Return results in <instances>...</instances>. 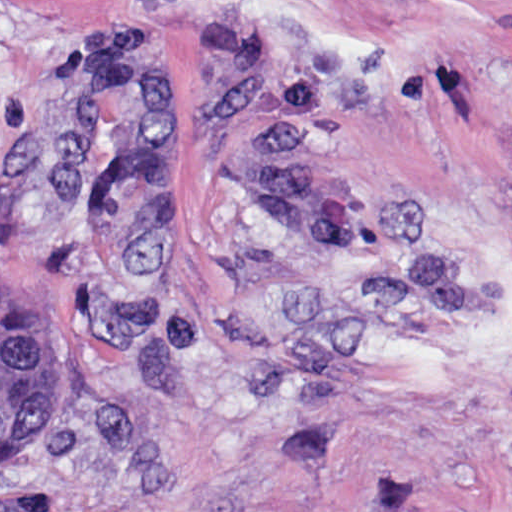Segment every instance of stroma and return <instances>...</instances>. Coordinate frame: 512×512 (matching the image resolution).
I'll return each mask as SVG.
<instances>
[{
  "instance_id": "stroma-1",
  "label": "stroma",
  "mask_w": 512,
  "mask_h": 512,
  "mask_svg": "<svg viewBox=\"0 0 512 512\" xmlns=\"http://www.w3.org/2000/svg\"><path fill=\"white\" fill-rule=\"evenodd\" d=\"M0 310L68 359L0 512H512V0H0Z\"/></svg>"
}]
</instances>
